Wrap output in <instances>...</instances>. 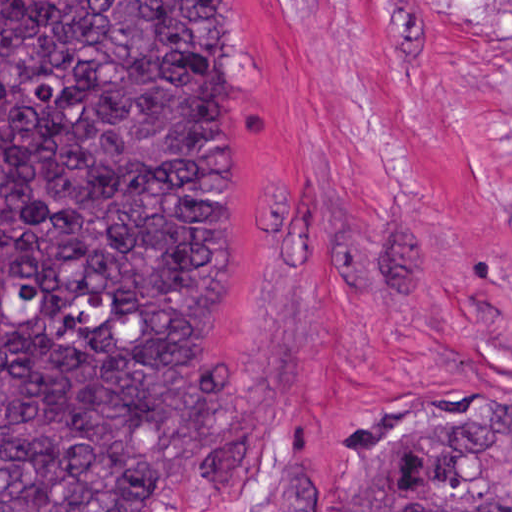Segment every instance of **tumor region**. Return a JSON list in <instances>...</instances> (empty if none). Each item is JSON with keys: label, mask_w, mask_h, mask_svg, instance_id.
Masks as SVG:
<instances>
[{"label": "tumor region", "mask_w": 512, "mask_h": 512, "mask_svg": "<svg viewBox=\"0 0 512 512\" xmlns=\"http://www.w3.org/2000/svg\"><path fill=\"white\" fill-rule=\"evenodd\" d=\"M221 299L215 1H0V512H188L260 470L187 375ZM344 512H512V410L404 401Z\"/></svg>", "instance_id": "e687c5a6"}]
</instances>
